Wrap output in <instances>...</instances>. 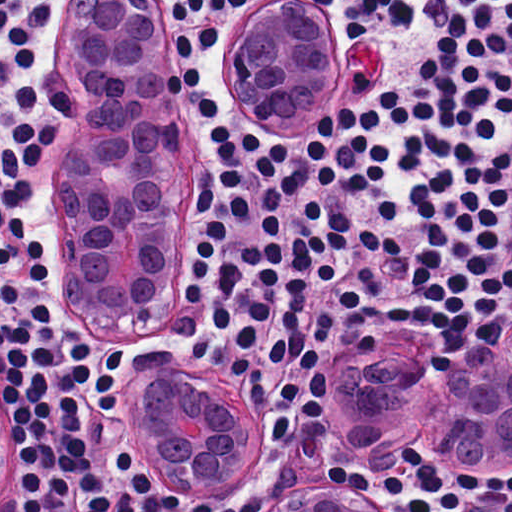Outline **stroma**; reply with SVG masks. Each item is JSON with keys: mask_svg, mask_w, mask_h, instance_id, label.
<instances>
[{"mask_svg": "<svg viewBox=\"0 0 512 512\" xmlns=\"http://www.w3.org/2000/svg\"><path fill=\"white\" fill-rule=\"evenodd\" d=\"M148 16L157 20L165 40L171 64V12H162V0H143ZM289 7L309 13L315 20L321 43L320 89L331 97L328 111L337 105L355 103L379 89L398 84L395 69L396 37L380 34L367 27L363 35H349L346 22L320 0H236L221 38L206 47L205 53L192 59L202 66V80L214 100L222 106V117L240 132L255 130L267 139H281L294 151L300 173V191L285 201L281 236H268L261 219L257 174L250 155L242 156L246 198L250 204L248 223L237 222L228 211L221 192L217 152L202 117L188 94H183L197 133V235L199 233V189L204 182L213 187L214 206L232 241L260 240L266 244H285L302 222L303 201H317L334 206L348 216L376 228L394 229V201L398 188L401 156V128H382L377 135L391 154V162L376 189L367 195H323L315 186L313 170L307 166V140L311 128H284L276 125L256 92L249 71L250 31L257 19L272 8ZM46 59L51 71L65 83L72 101L71 122L59 139L62 157L58 189L64 174L70 177L79 155V131L75 126V100L84 102L81 65L74 55L63 28L55 29L46 45ZM57 189V193H58ZM382 283L376 301H388L405 307L439 310L445 315V327L428 334L420 330L386 332L382 330L357 337L341 334L320 350V364L327 379L326 402L317 418L307 422L300 413L291 422L286 445L268 441L267 430L273 425V407L256 411L246 402L228 370V337L215 335L207 317L187 302L180 331L161 342H130L103 335L108 342L123 348L135 365L115 388L117 404H128L148 378L157 377L179 387L203 391L212 398L220 414L230 421H247L252 417L260 431V459L254 474L231 485L243 500L263 498V508L275 498H302L305 485L317 480L333 483L325 475L326 465H340L363 476L395 474L417 485L412 471L404 464L410 448L420 446L428 454L462 472L479 476H512V456L498 452H473L417 434L394 435L369 450L365 464L340 460L334 450V409L343 407L350 371L360 363H374L395 369L422 383L436 384L441 379L440 365L447 358L475 359L483 349L496 343L512 319L509 312L493 340L472 338L468 329H458L447 313L416 290L410 282L413 263L397 250L384 253L380 260H370ZM430 269L416 265L417 281ZM58 289V286H57ZM120 370L124 360L119 356ZM121 407V405H120ZM129 411V410H128ZM130 459L135 461L128 454ZM137 465V464H136ZM138 466V465H137ZM139 467V466H138ZM217 489V488H173ZM381 512H410L402 495L382 497L378 488L362 491ZM180 497L196 509H224L250 512L242 501L215 502ZM0 512H8L1 492ZM435 512H451L441 510ZM462 512H504L502 501L483 499L477 506Z\"/></svg>", "mask_w": 512, "mask_h": 512, "instance_id": "stroma-1", "label": "stroma"}]
</instances>
